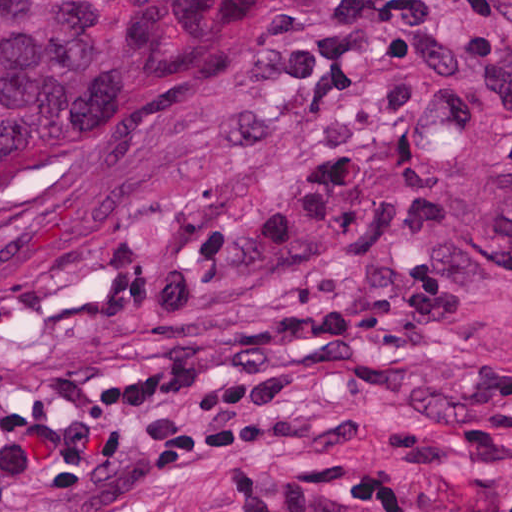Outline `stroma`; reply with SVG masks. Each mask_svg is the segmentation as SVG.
<instances>
[{
    "instance_id": "obj_1",
    "label": "stroma",
    "mask_w": 512,
    "mask_h": 512,
    "mask_svg": "<svg viewBox=\"0 0 512 512\" xmlns=\"http://www.w3.org/2000/svg\"><path fill=\"white\" fill-rule=\"evenodd\" d=\"M333 456L512 512V0H256L199 115L0 222V512Z\"/></svg>"
}]
</instances>
